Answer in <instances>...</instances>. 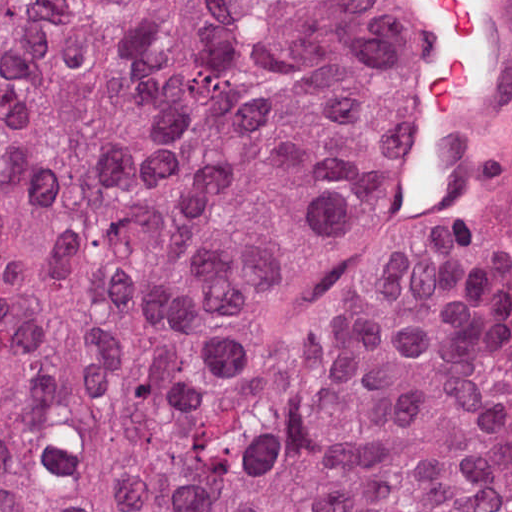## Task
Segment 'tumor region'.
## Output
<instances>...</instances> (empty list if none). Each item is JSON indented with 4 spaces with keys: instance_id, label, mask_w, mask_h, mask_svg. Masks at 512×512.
<instances>
[{
    "instance_id": "obj_1",
    "label": "tumor region",
    "mask_w": 512,
    "mask_h": 512,
    "mask_svg": "<svg viewBox=\"0 0 512 512\" xmlns=\"http://www.w3.org/2000/svg\"><path fill=\"white\" fill-rule=\"evenodd\" d=\"M380 0H0V512H505L512 170L382 127Z\"/></svg>"
}]
</instances>
